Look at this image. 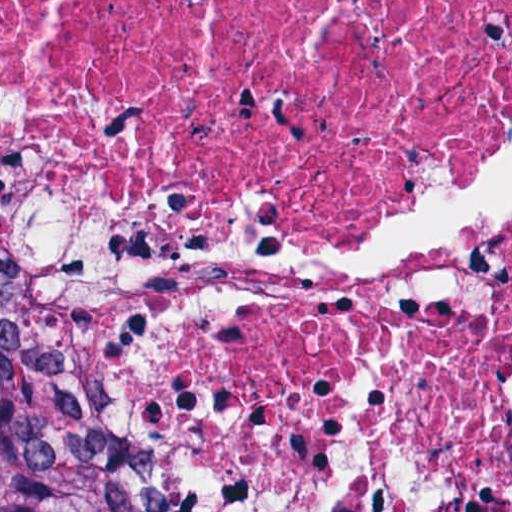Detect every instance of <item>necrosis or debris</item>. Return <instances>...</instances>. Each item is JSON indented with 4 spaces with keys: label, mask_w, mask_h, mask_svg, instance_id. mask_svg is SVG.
<instances>
[{
    "label": "necrosis or debris",
    "mask_w": 512,
    "mask_h": 512,
    "mask_svg": "<svg viewBox=\"0 0 512 512\" xmlns=\"http://www.w3.org/2000/svg\"><path fill=\"white\" fill-rule=\"evenodd\" d=\"M0 266L152 512H512V0H0Z\"/></svg>",
    "instance_id": "1"
}]
</instances>
